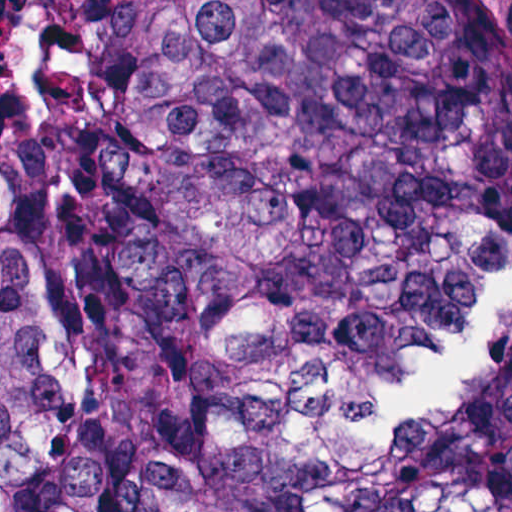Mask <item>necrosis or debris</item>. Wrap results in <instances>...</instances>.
I'll return each instance as SVG.
<instances>
[{"label": "necrosis or debris", "mask_w": 512, "mask_h": 512, "mask_svg": "<svg viewBox=\"0 0 512 512\" xmlns=\"http://www.w3.org/2000/svg\"><path fill=\"white\" fill-rule=\"evenodd\" d=\"M34 90L24 53V0H0V103H25Z\"/></svg>", "instance_id": "1"}]
</instances>
